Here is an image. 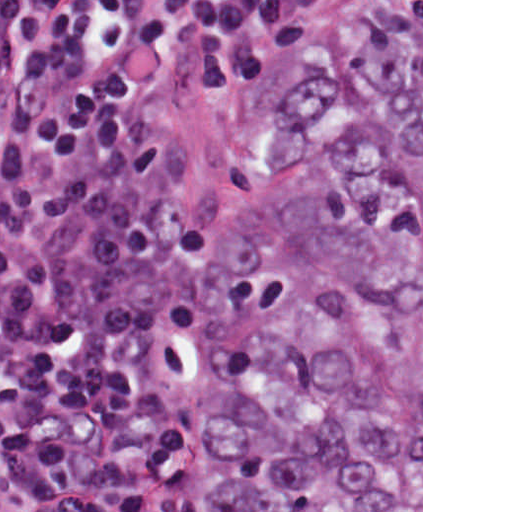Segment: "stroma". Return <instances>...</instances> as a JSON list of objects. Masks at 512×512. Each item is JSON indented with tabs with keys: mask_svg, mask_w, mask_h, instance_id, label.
Segmentation results:
<instances>
[{
	"mask_svg": "<svg viewBox=\"0 0 512 512\" xmlns=\"http://www.w3.org/2000/svg\"><path fill=\"white\" fill-rule=\"evenodd\" d=\"M367 2L421 3V512H423V0H294V50L317 28L341 12ZM135 106L188 158L184 187L194 214L213 217L221 209L215 242L236 177L255 141L265 109L256 120V89L240 96L193 90L183 73L180 51L169 45L139 51L135 58ZM266 108V107H265ZM210 270V274H211ZM210 279V277H209ZM207 318L198 351L183 388L170 452L166 511L183 473L186 417L202 363Z\"/></svg>",
	"mask_w": 512,
	"mask_h": 512,
	"instance_id": "35a3bbf8",
	"label": "stroma"
}]
</instances>
